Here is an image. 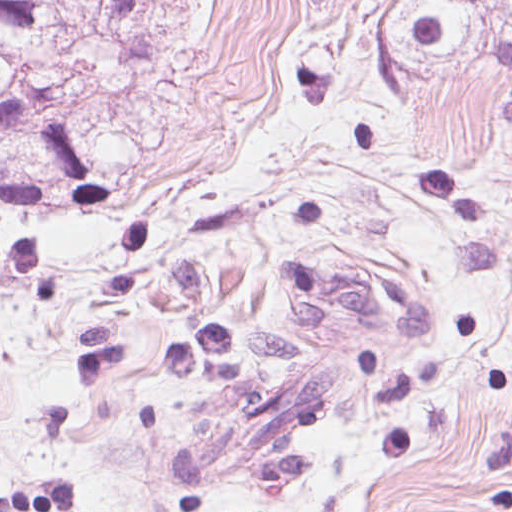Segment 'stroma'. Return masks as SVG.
<instances>
[{
	"mask_svg": "<svg viewBox=\"0 0 512 512\" xmlns=\"http://www.w3.org/2000/svg\"><path fill=\"white\" fill-rule=\"evenodd\" d=\"M335 0L169 512H512V134Z\"/></svg>",
	"mask_w": 512,
	"mask_h": 512,
	"instance_id": "1",
	"label": "stroma"
}]
</instances>
